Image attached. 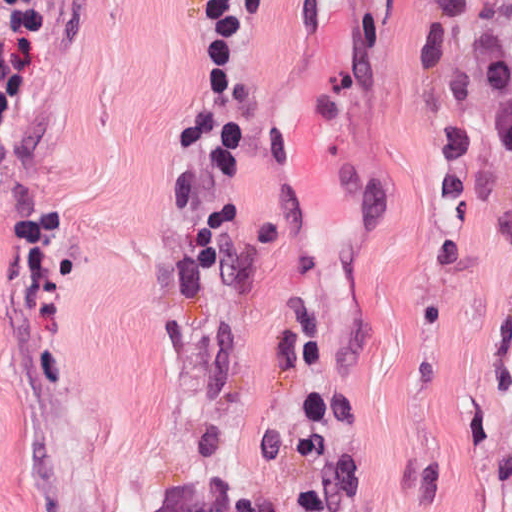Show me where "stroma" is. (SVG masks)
Here are the masks:
<instances>
[{
  "mask_svg": "<svg viewBox=\"0 0 512 512\" xmlns=\"http://www.w3.org/2000/svg\"><path fill=\"white\" fill-rule=\"evenodd\" d=\"M209 1L46 0L43 124L0 165V512H156L213 428L239 494L295 490L255 444L304 428L307 347L341 512H512V157L480 145L465 200L434 167L466 30L420 75L413 0H269L195 288L163 174Z\"/></svg>",
  "mask_w": 512,
  "mask_h": 512,
  "instance_id": "stroma-1",
  "label": "stroma"
}]
</instances>
